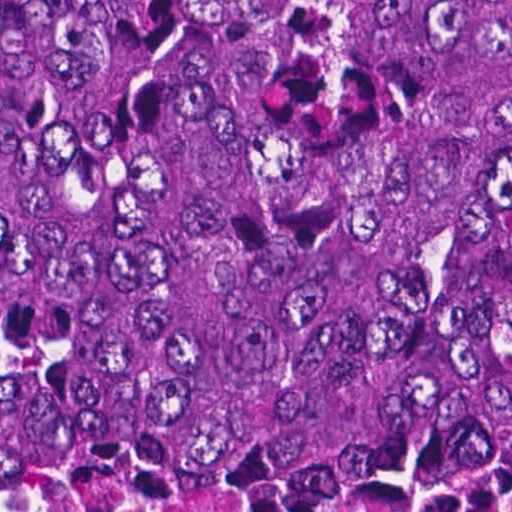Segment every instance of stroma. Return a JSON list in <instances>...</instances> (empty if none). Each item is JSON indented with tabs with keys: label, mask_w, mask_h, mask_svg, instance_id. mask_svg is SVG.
Returning <instances> with one entry per match:
<instances>
[{
	"label": "stroma",
	"mask_w": 512,
	"mask_h": 512,
	"mask_svg": "<svg viewBox=\"0 0 512 512\" xmlns=\"http://www.w3.org/2000/svg\"><path fill=\"white\" fill-rule=\"evenodd\" d=\"M0 512H512L508 509H0Z\"/></svg>",
	"instance_id": "1"
}]
</instances>
